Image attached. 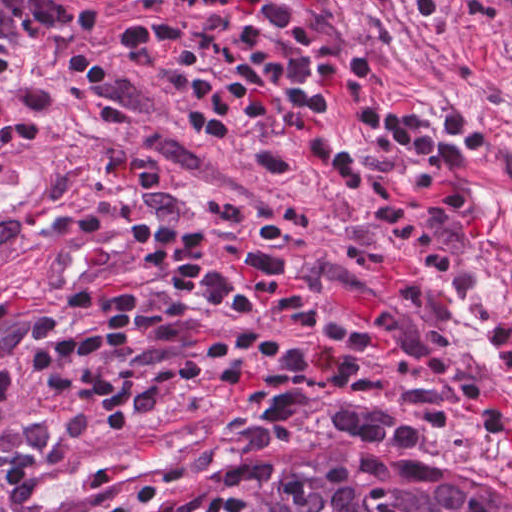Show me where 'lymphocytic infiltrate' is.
Returning a JSON list of instances; mask_svg holds the SVG:
<instances>
[{
    "label": "lymphocytic infiltrate",
    "instance_id": "f902f5d3",
    "mask_svg": "<svg viewBox=\"0 0 512 512\" xmlns=\"http://www.w3.org/2000/svg\"><path fill=\"white\" fill-rule=\"evenodd\" d=\"M50 461V460H49ZM185 471L176 469L171 472H167L164 474H160L151 480L145 482L144 484L134 488L133 490L127 492L126 494L118 497L117 499L103 505L98 510L94 512H114L123 502L126 500L137 496L146 491L159 489L165 487L168 483L172 482L176 478L180 477ZM3 512H7L5 509Z\"/></svg>",
    "mask_w": 512,
    "mask_h": 512
}]
</instances>
